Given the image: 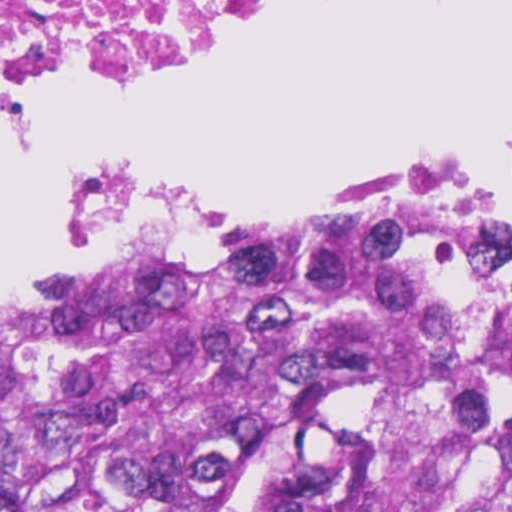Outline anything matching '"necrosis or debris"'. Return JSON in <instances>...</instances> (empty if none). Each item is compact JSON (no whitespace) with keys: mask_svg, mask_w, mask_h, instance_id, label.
<instances>
[{"mask_svg":"<svg viewBox=\"0 0 512 512\" xmlns=\"http://www.w3.org/2000/svg\"><path fill=\"white\" fill-rule=\"evenodd\" d=\"M323 0H0V88L110 92Z\"/></svg>","mask_w":512,"mask_h":512,"instance_id":"necrosis-or-debris-1","label":"necrosis or debris"}]
</instances>
